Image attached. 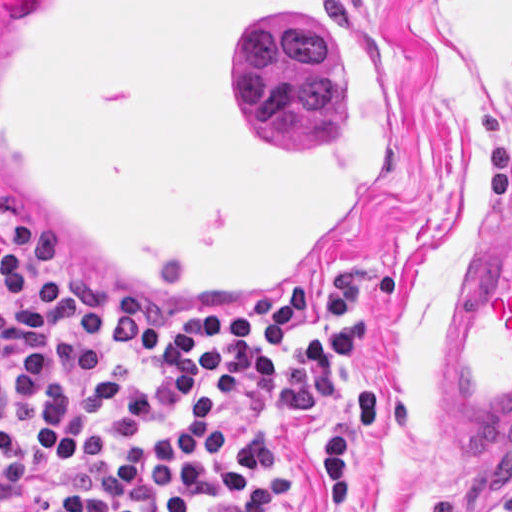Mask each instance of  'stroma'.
Returning a JSON list of instances; mask_svg holds the SVG:
<instances>
[{
    "mask_svg": "<svg viewBox=\"0 0 512 512\" xmlns=\"http://www.w3.org/2000/svg\"><path fill=\"white\" fill-rule=\"evenodd\" d=\"M339 1L393 50L414 100V158L402 188L313 287L357 274L395 280L394 307L353 367L390 386L392 399L380 445L362 425L354 438L364 512H420L427 497H440L444 512L512 511V443L472 452L444 422L467 258L512 215V0ZM9 212L0 203V218ZM105 288L179 316L283 312L184 309ZM280 443L293 490L278 512H328L327 425L321 418Z\"/></svg>",
    "mask_w": 512,
    "mask_h": 512,
    "instance_id": "1",
    "label": "stroma"
}]
</instances>
